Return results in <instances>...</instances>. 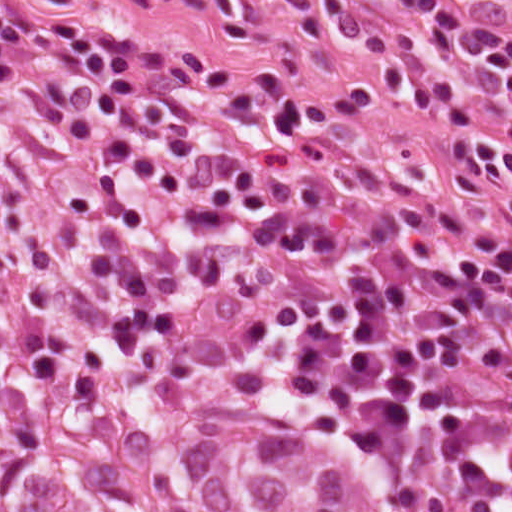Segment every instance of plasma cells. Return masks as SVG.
Instances as JSON below:
<instances>
[{"label":"plasma cells","instance_id":"obj_1","mask_svg":"<svg viewBox=\"0 0 512 512\" xmlns=\"http://www.w3.org/2000/svg\"><path fill=\"white\" fill-rule=\"evenodd\" d=\"M82 0H0V72L58 159L34 166L27 240L64 297L193 361L282 415L400 457L454 512H512V262L441 205L315 130L294 101L108 25ZM414 28L327 0L421 109L457 95L440 47L507 91L512 35L454 0H398ZM461 200L512 217V139L450 135Z\"/></svg>","mask_w":512,"mask_h":512}]
</instances>
